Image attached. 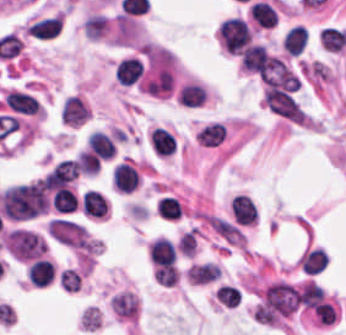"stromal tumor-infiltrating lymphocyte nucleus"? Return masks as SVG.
I'll use <instances>...</instances> for the list:
<instances>
[{
  "mask_svg": "<svg viewBox=\"0 0 346 335\" xmlns=\"http://www.w3.org/2000/svg\"><path fill=\"white\" fill-rule=\"evenodd\" d=\"M217 33L223 48L239 56L251 41V33L245 21L238 17L228 18L221 23Z\"/></svg>",
  "mask_w": 346,
  "mask_h": 335,
  "instance_id": "bc302bb0",
  "label": "stromal tumor-infiltrating lymphocyte nucleus"
},
{
  "mask_svg": "<svg viewBox=\"0 0 346 335\" xmlns=\"http://www.w3.org/2000/svg\"><path fill=\"white\" fill-rule=\"evenodd\" d=\"M230 209L232 218L236 224H255L256 210L249 196L239 193L232 198Z\"/></svg>",
  "mask_w": 346,
  "mask_h": 335,
  "instance_id": "52c7bb5b",
  "label": "stromal tumor-infiltrating lymphocyte nucleus"
},
{
  "mask_svg": "<svg viewBox=\"0 0 346 335\" xmlns=\"http://www.w3.org/2000/svg\"><path fill=\"white\" fill-rule=\"evenodd\" d=\"M148 256L153 266L170 267L174 256V247L167 239L157 238L148 245Z\"/></svg>",
  "mask_w": 346,
  "mask_h": 335,
  "instance_id": "3290ff9b",
  "label": "stromal tumor-infiltrating lymphocyte nucleus"
},
{
  "mask_svg": "<svg viewBox=\"0 0 346 335\" xmlns=\"http://www.w3.org/2000/svg\"><path fill=\"white\" fill-rule=\"evenodd\" d=\"M87 116L88 112L84 102L76 95H69L65 99L61 107V118L64 123L78 126Z\"/></svg>",
  "mask_w": 346,
  "mask_h": 335,
  "instance_id": "abfb95fc",
  "label": "stromal tumor-infiltrating lymphocyte nucleus"
},
{
  "mask_svg": "<svg viewBox=\"0 0 346 335\" xmlns=\"http://www.w3.org/2000/svg\"><path fill=\"white\" fill-rule=\"evenodd\" d=\"M113 187L119 192L133 190L138 182L133 166L127 162H120L112 172Z\"/></svg>",
  "mask_w": 346,
  "mask_h": 335,
  "instance_id": "9ea309e8",
  "label": "stromal tumor-infiltrating lymphocyte nucleus"
},
{
  "mask_svg": "<svg viewBox=\"0 0 346 335\" xmlns=\"http://www.w3.org/2000/svg\"><path fill=\"white\" fill-rule=\"evenodd\" d=\"M87 149L96 159H110L115 146L109 135L96 130L87 141Z\"/></svg>",
  "mask_w": 346,
  "mask_h": 335,
  "instance_id": "f3e2335f",
  "label": "stromal tumor-infiltrating lymphocyte nucleus"
},
{
  "mask_svg": "<svg viewBox=\"0 0 346 335\" xmlns=\"http://www.w3.org/2000/svg\"><path fill=\"white\" fill-rule=\"evenodd\" d=\"M29 283L45 286L54 276V266L43 259L33 260L26 272Z\"/></svg>",
  "mask_w": 346,
  "mask_h": 335,
  "instance_id": "4f13568d",
  "label": "stromal tumor-infiltrating lymphocyte nucleus"
},
{
  "mask_svg": "<svg viewBox=\"0 0 346 335\" xmlns=\"http://www.w3.org/2000/svg\"><path fill=\"white\" fill-rule=\"evenodd\" d=\"M280 44L286 54L297 56L305 44V30L301 25H293L284 32Z\"/></svg>",
  "mask_w": 346,
  "mask_h": 335,
  "instance_id": "2a367800",
  "label": "stromal tumor-infiltrating lymphocyte nucleus"
},
{
  "mask_svg": "<svg viewBox=\"0 0 346 335\" xmlns=\"http://www.w3.org/2000/svg\"><path fill=\"white\" fill-rule=\"evenodd\" d=\"M81 208L87 215L104 218L108 211V203L100 192L87 190L82 196Z\"/></svg>",
  "mask_w": 346,
  "mask_h": 335,
  "instance_id": "4803ca6d",
  "label": "stromal tumor-infiltrating lymphocyte nucleus"
},
{
  "mask_svg": "<svg viewBox=\"0 0 346 335\" xmlns=\"http://www.w3.org/2000/svg\"><path fill=\"white\" fill-rule=\"evenodd\" d=\"M220 273V267L211 262H204L191 265L185 276L190 282L203 284L216 279Z\"/></svg>",
  "mask_w": 346,
  "mask_h": 335,
  "instance_id": "4245b91a",
  "label": "stromal tumor-infiltrating lymphocyte nucleus"
},
{
  "mask_svg": "<svg viewBox=\"0 0 346 335\" xmlns=\"http://www.w3.org/2000/svg\"><path fill=\"white\" fill-rule=\"evenodd\" d=\"M296 296L300 304L314 309L324 301L321 286L309 279L301 285Z\"/></svg>",
  "mask_w": 346,
  "mask_h": 335,
  "instance_id": "4c9ddf68",
  "label": "stromal tumor-infiltrating lymphocyte nucleus"
},
{
  "mask_svg": "<svg viewBox=\"0 0 346 335\" xmlns=\"http://www.w3.org/2000/svg\"><path fill=\"white\" fill-rule=\"evenodd\" d=\"M50 203L56 213H71L77 204V197L71 187H62L53 192Z\"/></svg>",
  "mask_w": 346,
  "mask_h": 335,
  "instance_id": "2761f720",
  "label": "stromal tumor-infiltrating lymphocyte nucleus"
},
{
  "mask_svg": "<svg viewBox=\"0 0 346 335\" xmlns=\"http://www.w3.org/2000/svg\"><path fill=\"white\" fill-rule=\"evenodd\" d=\"M249 13L257 26L271 27L275 23L276 13L271 5L264 1L250 4Z\"/></svg>",
  "mask_w": 346,
  "mask_h": 335,
  "instance_id": "3c572f05",
  "label": "stromal tumor-infiltrating lymphocyte nucleus"
},
{
  "mask_svg": "<svg viewBox=\"0 0 346 335\" xmlns=\"http://www.w3.org/2000/svg\"><path fill=\"white\" fill-rule=\"evenodd\" d=\"M226 137L225 129L222 123L212 122L204 126L197 133L196 142L199 144L216 146Z\"/></svg>",
  "mask_w": 346,
  "mask_h": 335,
  "instance_id": "42bb06b2",
  "label": "stromal tumor-infiltrating lymphocyte nucleus"
},
{
  "mask_svg": "<svg viewBox=\"0 0 346 335\" xmlns=\"http://www.w3.org/2000/svg\"><path fill=\"white\" fill-rule=\"evenodd\" d=\"M206 99L205 90L194 83H187L180 88L178 93V102L180 105L196 107Z\"/></svg>",
  "mask_w": 346,
  "mask_h": 335,
  "instance_id": "9e4306bb",
  "label": "stromal tumor-infiltrating lymphocyte nucleus"
},
{
  "mask_svg": "<svg viewBox=\"0 0 346 335\" xmlns=\"http://www.w3.org/2000/svg\"><path fill=\"white\" fill-rule=\"evenodd\" d=\"M85 34L90 39H97L106 31L108 24L103 14H90L82 25Z\"/></svg>",
  "mask_w": 346,
  "mask_h": 335,
  "instance_id": "04cf8593",
  "label": "stromal tumor-infiltrating lymphocyte nucleus"
},
{
  "mask_svg": "<svg viewBox=\"0 0 346 335\" xmlns=\"http://www.w3.org/2000/svg\"><path fill=\"white\" fill-rule=\"evenodd\" d=\"M320 46L329 51H341L342 31L331 26H324L321 33Z\"/></svg>",
  "mask_w": 346,
  "mask_h": 335,
  "instance_id": "e9af9c67",
  "label": "stromal tumor-infiltrating lymphocyte nucleus"
},
{
  "mask_svg": "<svg viewBox=\"0 0 346 335\" xmlns=\"http://www.w3.org/2000/svg\"><path fill=\"white\" fill-rule=\"evenodd\" d=\"M264 48V45L258 44H250L245 48L241 56V67L255 73Z\"/></svg>",
  "mask_w": 346,
  "mask_h": 335,
  "instance_id": "782c7336",
  "label": "stromal tumor-infiltrating lymphocyte nucleus"
},
{
  "mask_svg": "<svg viewBox=\"0 0 346 335\" xmlns=\"http://www.w3.org/2000/svg\"><path fill=\"white\" fill-rule=\"evenodd\" d=\"M215 299L222 305L234 306L240 299V293L228 284L216 288Z\"/></svg>",
  "mask_w": 346,
  "mask_h": 335,
  "instance_id": "cac63f63",
  "label": "stromal tumor-infiltrating lymphocyte nucleus"
},
{
  "mask_svg": "<svg viewBox=\"0 0 346 335\" xmlns=\"http://www.w3.org/2000/svg\"><path fill=\"white\" fill-rule=\"evenodd\" d=\"M158 213L162 219H176L180 213L173 197H165L156 203Z\"/></svg>",
  "mask_w": 346,
  "mask_h": 335,
  "instance_id": "2e467ee5",
  "label": "stromal tumor-infiltrating lymphocyte nucleus"
},
{
  "mask_svg": "<svg viewBox=\"0 0 346 335\" xmlns=\"http://www.w3.org/2000/svg\"><path fill=\"white\" fill-rule=\"evenodd\" d=\"M80 281V276L72 268H65L59 277L60 287L72 293L79 290Z\"/></svg>",
  "mask_w": 346,
  "mask_h": 335,
  "instance_id": "7eef579d",
  "label": "stromal tumor-infiltrating lymphocyte nucleus"
}]
</instances>
